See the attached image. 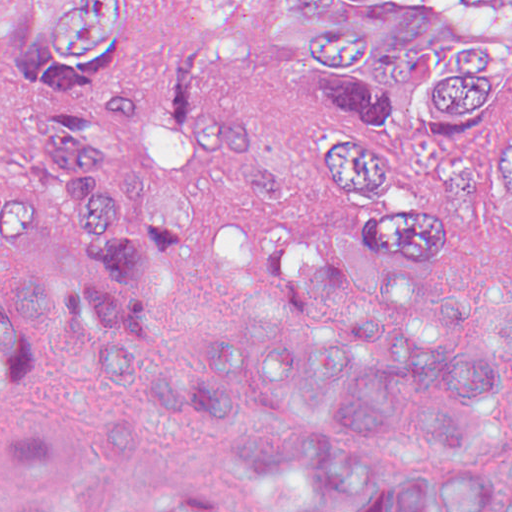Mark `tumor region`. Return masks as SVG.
<instances>
[{"label": "tumor region", "mask_w": 512, "mask_h": 512, "mask_svg": "<svg viewBox=\"0 0 512 512\" xmlns=\"http://www.w3.org/2000/svg\"><path fill=\"white\" fill-rule=\"evenodd\" d=\"M482 9L497 0H468ZM313 20L307 81L382 83L440 72L434 117L446 130L487 120L507 62L496 46L466 37L440 47L398 41L361 0H283ZM142 34L133 0H0V56H21L38 123L11 194H143L197 201L207 162L242 174L261 193L283 185L254 145L245 110L211 96L215 38L180 36L145 82L135 67ZM512 109L508 98L504 118ZM369 145H441L397 120L386 136L322 140V167Z\"/></svg>", "instance_id": "1"}]
</instances>
